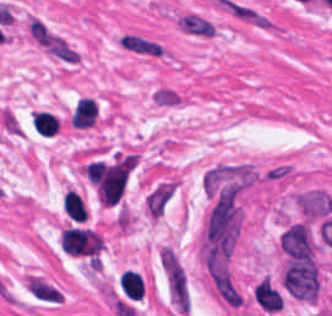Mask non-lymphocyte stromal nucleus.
<instances>
[{
    "label": "non-lymphocyte stromal nucleus",
    "instance_id": "dd21d789",
    "mask_svg": "<svg viewBox=\"0 0 332 316\" xmlns=\"http://www.w3.org/2000/svg\"><path fill=\"white\" fill-rule=\"evenodd\" d=\"M161 271L171 306L186 316L190 309L189 278L175 247L164 246Z\"/></svg>",
    "mask_w": 332,
    "mask_h": 316
},
{
    "label": "non-lymphocyte stromal nucleus",
    "instance_id": "a72fc3eb",
    "mask_svg": "<svg viewBox=\"0 0 332 316\" xmlns=\"http://www.w3.org/2000/svg\"><path fill=\"white\" fill-rule=\"evenodd\" d=\"M283 288L298 300L315 301L318 272L313 262L289 261L283 273Z\"/></svg>",
    "mask_w": 332,
    "mask_h": 316
},
{
    "label": "non-lymphocyte stromal nucleus",
    "instance_id": "3746e769",
    "mask_svg": "<svg viewBox=\"0 0 332 316\" xmlns=\"http://www.w3.org/2000/svg\"><path fill=\"white\" fill-rule=\"evenodd\" d=\"M25 290L34 300L48 305L62 301V289L46 278L29 275L26 277Z\"/></svg>",
    "mask_w": 332,
    "mask_h": 316
},
{
    "label": "non-lymphocyte stromal nucleus",
    "instance_id": "fc2b8d12",
    "mask_svg": "<svg viewBox=\"0 0 332 316\" xmlns=\"http://www.w3.org/2000/svg\"><path fill=\"white\" fill-rule=\"evenodd\" d=\"M176 22L179 30L193 37H213L216 30L215 23L193 12L180 14Z\"/></svg>",
    "mask_w": 332,
    "mask_h": 316
},
{
    "label": "non-lymphocyte stromal nucleus",
    "instance_id": "81446118",
    "mask_svg": "<svg viewBox=\"0 0 332 316\" xmlns=\"http://www.w3.org/2000/svg\"><path fill=\"white\" fill-rule=\"evenodd\" d=\"M298 199L302 213L314 219L324 216L332 208V199L327 193L319 191L301 193Z\"/></svg>",
    "mask_w": 332,
    "mask_h": 316
},
{
    "label": "non-lymphocyte stromal nucleus",
    "instance_id": "7c5642bf",
    "mask_svg": "<svg viewBox=\"0 0 332 316\" xmlns=\"http://www.w3.org/2000/svg\"><path fill=\"white\" fill-rule=\"evenodd\" d=\"M228 10L230 15L259 29H270L273 25V20L245 4L230 1Z\"/></svg>",
    "mask_w": 332,
    "mask_h": 316
},
{
    "label": "non-lymphocyte stromal nucleus",
    "instance_id": "9d01c50a",
    "mask_svg": "<svg viewBox=\"0 0 332 316\" xmlns=\"http://www.w3.org/2000/svg\"><path fill=\"white\" fill-rule=\"evenodd\" d=\"M173 185L168 182H161L148 198L147 208L151 216L161 217L171 196Z\"/></svg>",
    "mask_w": 332,
    "mask_h": 316
},
{
    "label": "non-lymphocyte stromal nucleus",
    "instance_id": "2ac0efb1",
    "mask_svg": "<svg viewBox=\"0 0 332 316\" xmlns=\"http://www.w3.org/2000/svg\"><path fill=\"white\" fill-rule=\"evenodd\" d=\"M119 45L133 51L161 54L160 47L152 41L142 39L133 35H124L118 39Z\"/></svg>",
    "mask_w": 332,
    "mask_h": 316
}]
</instances>
